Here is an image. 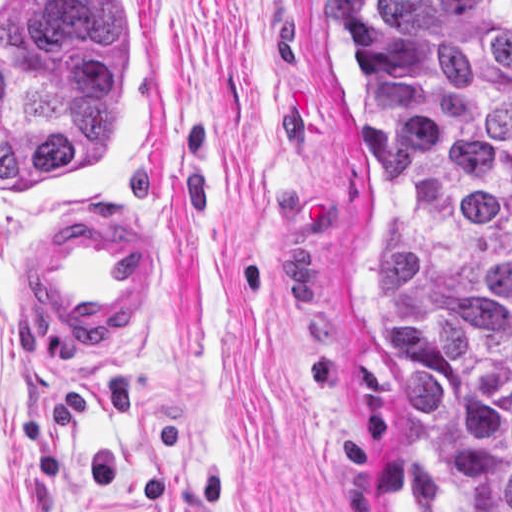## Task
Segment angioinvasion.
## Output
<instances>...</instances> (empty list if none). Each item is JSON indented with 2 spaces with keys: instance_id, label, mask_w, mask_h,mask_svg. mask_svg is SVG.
Returning <instances> with one entry per match:
<instances>
[{
  "instance_id": "obj_1",
  "label": "angioinvasion",
  "mask_w": 512,
  "mask_h": 512,
  "mask_svg": "<svg viewBox=\"0 0 512 512\" xmlns=\"http://www.w3.org/2000/svg\"><path fill=\"white\" fill-rule=\"evenodd\" d=\"M162 144L149 1H0V230L99 216Z\"/></svg>"
}]
</instances>
